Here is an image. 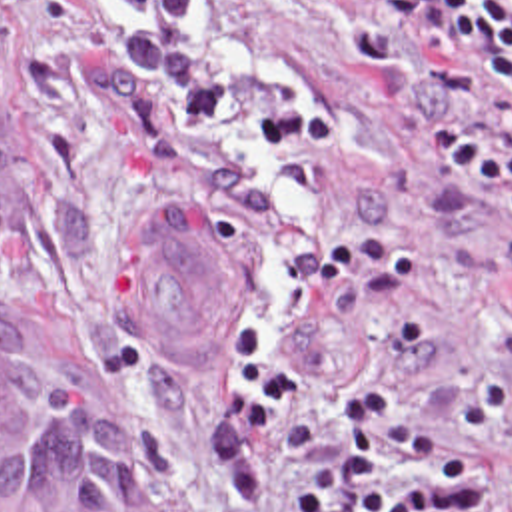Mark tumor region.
Masks as SVG:
<instances>
[{"instance_id":"1","label":"tumor region","mask_w":512,"mask_h":512,"mask_svg":"<svg viewBox=\"0 0 512 512\" xmlns=\"http://www.w3.org/2000/svg\"><path fill=\"white\" fill-rule=\"evenodd\" d=\"M20 242L15 142L0 120V276ZM120 310L174 360H212L236 344V258L182 208L146 216L116 258ZM0 512H106L98 424L56 360L0 308Z\"/></svg>"}]
</instances>
